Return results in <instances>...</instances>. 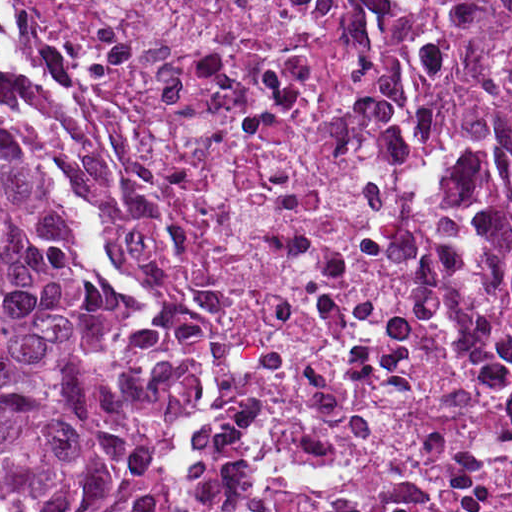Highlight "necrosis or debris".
<instances>
[{
	"label": "necrosis or debris",
	"instance_id": "1",
	"mask_svg": "<svg viewBox=\"0 0 512 512\" xmlns=\"http://www.w3.org/2000/svg\"><path fill=\"white\" fill-rule=\"evenodd\" d=\"M98 267L211 355L188 512H512V38L416 0H0Z\"/></svg>",
	"mask_w": 512,
	"mask_h": 512
}]
</instances>
